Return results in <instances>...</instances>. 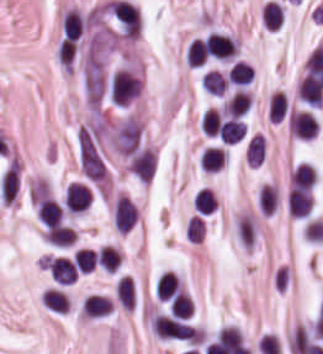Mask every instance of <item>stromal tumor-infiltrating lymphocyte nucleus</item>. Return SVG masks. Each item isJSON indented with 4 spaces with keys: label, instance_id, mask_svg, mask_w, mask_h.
Instances as JSON below:
<instances>
[{
    "label": "stromal tumor-infiltrating lymphocyte nucleus",
    "instance_id": "bc302bb0",
    "mask_svg": "<svg viewBox=\"0 0 323 354\" xmlns=\"http://www.w3.org/2000/svg\"><path fill=\"white\" fill-rule=\"evenodd\" d=\"M109 9L125 38L136 39L141 28L137 8L126 1H113Z\"/></svg>",
    "mask_w": 323,
    "mask_h": 354
},
{
    "label": "stromal tumor-infiltrating lymphocyte nucleus",
    "instance_id": "52c7bb5b",
    "mask_svg": "<svg viewBox=\"0 0 323 354\" xmlns=\"http://www.w3.org/2000/svg\"><path fill=\"white\" fill-rule=\"evenodd\" d=\"M288 130L296 136L311 139L316 135L317 120L305 110H292L289 116Z\"/></svg>",
    "mask_w": 323,
    "mask_h": 354
},
{
    "label": "stromal tumor-infiltrating lymphocyte nucleus",
    "instance_id": "3290ff9b",
    "mask_svg": "<svg viewBox=\"0 0 323 354\" xmlns=\"http://www.w3.org/2000/svg\"><path fill=\"white\" fill-rule=\"evenodd\" d=\"M210 56L232 58L237 53V43L229 35L211 33L204 40Z\"/></svg>",
    "mask_w": 323,
    "mask_h": 354
},
{
    "label": "stromal tumor-infiltrating lymphocyte nucleus",
    "instance_id": "abfb95fc",
    "mask_svg": "<svg viewBox=\"0 0 323 354\" xmlns=\"http://www.w3.org/2000/svg\"><path fill=\"white\" fill-rule=\"evenodd\" d=\"M313 207L309 191L292 188L287 197V209L291 218H304Z\"/></svg>",
    "mask_w": 323,
    "mask_h": 354
},
{
    "label": "stromal tumor-infiltrating lymphocyte nucleus",
    "instance_id": "9ea309e8",
    "mask_svg": "<svg viewBox=\"0 0 323 354\" xmlns=\"http://www.w3.org/2000/svg\"><path fill=\"white\" fill-rule=\"evenodd\" d=\"M47 267L51 278L60 284H68L77 278V267L63 256L52 257Z\"/></svg>",
    "mask_w": 323,
    "mask_h": 354
},
{
    "label": "stromal tumor-infiltrating lymphocyte nucleus",
    "instance_id": "f3e2335f",
    "mask_svg": "<svg viewBox=\"0 0 323 354\" xmlns=\"http://www.w3.org/2000/svg\"><path fill=\"white\" fill-rule=\"evenodd\" d=\"M136 220V209L131 200L119 195L115 205L113 222L119 231H128Z\"/></svg>",
    "mask_w": 323,
    "mask_h": 354
},
{
    "label": "stromal tumor-infiltrating lymphocyte nucleus",
    "instance_id": "4f13568d",
    "mask_svg": "<svg viewBox=\"0 0 323 354\" xmlns=\"http://www.w3.org/2000/svg\"><path fill=\"white\" fill-rule=\"evenodd\" d=\"M297 93L300 99L312 107H320L323 100V86L314 75L307 73L302 78Z\"/></svg>",
    "mask_w": 323,
    "mask_h": 354
},
{
    "label": "stromal tumor-infiltrating lymphocyte nucleus",
    "instance_id": "2a367800",
    "mask_svg": "<svg viewBox=\"0 0 323 354\" xmlns=\"http://www.w3.org/2000/svg\"><path fill=\"white\" fill-rule=\"evenodd\" d=\"M91 199L90 189L79 182H72L65 195L66 205L76 213L88 208Z\"/></svg>",
    "mask_w": 323,
    "mask_h": 354
},
{
    "label": "stromal tumor-infiltrating lymphocyte nucleus",
    "instance_id": "4803ca6d",
    "mask_svg": "<svg viewBox=\"0 0 323 354\" xmlns=\"http://www.w3.org/2000/svg\"><path fill=\"white\" fill-rule=\"evenodd\" d=\"M19 189V168L18 162L13 157L9 163L2 179L1 193L3 203H10L14 200Z\"/></svg>",
    "mask_w": 323,
    "mask_h": 354
},
{
    "label": "stromal tumor-infiltrating lymphocyte nucleus",
    "instance_id": "4245b91a",
    "mask_svg": "<svg viewBox=\"0 0 323 354\" xmlns=\"http://www.w3.org/2000/svg\"><path fill=\"white\" fill-rule=\"evenodd\" d=\"M266 153L263 134L250 133L244 142V157L249 163L260 164Z\"/></svg>",
    "mask_w": 323,
    "mask_h": 354
},
{
    "label": "stromal tumor-infiltrating lymphocyte nucleus",
    "instance_id": "4c9ddf68",
    "mask_svg": "<svg viewBox=\"0 0 323 354\" xmlns=\"http://www.w3.org/2000/svg\"><path fill=\"white\" fill-rule=\"evenodd\" d=\"M113 303L102 294H88L83 305L82 315L100 317L108 315Z\"/></svg>",
    "mask_w": 323,
    "mask_h": 354
},
{
    "label": "stromal tumor-infiltrating lymphocyte nucleus",
    "instance_id": "2761f720",
    "mask_svg": "<svg viewBox=\"0 0 323 354\" xmlns=\"http://www.w3.org/2000/svg\"><path fill=\"white\" fill-rule=\"evenodd\" d=\"M45 238L56 247H69L77 238L73 229L67 225H54L47 228Z\"/></svg>",
    "mask_w": 323,
    "mask_h": 354
},
{
    "label": "stromal tumor-infiltrating lymphocyte nucleus",
    "instance_id": "3c572f05",
    "mask_svg": "<svg viewBox=\"0 0 323 354\" xmlns=\"http://www.w3.org/2000/svg\"><path fill=\"white\" fill-rule=\"evenodd\" d=\"M83 17L76 9H68L63 14L62 30L67 40H77L83 31Z\"/></svg>",
    "mask_w": 323,
    "mask_h": 354
},
{
    "label": "stromal tumor-infiltrating lymphocyte nucleus",
    "instance_id": "42bb06b2",
    "mask_svg": "<svg viewBox=\"0 0 323 354\" xmlns=\"http://www.w3.org/2000/svg\"><path fill=\"white\" fill-rule=\"evenodd\" d=\"M253 78L252 67L248 62L235 61L231 67L226 81L237 86L250 84Z\"/></svg>",
    "mask_w": 323,
    "mask_h": 354
},
{
    "label": "stromal tumor-infiltrating lymphocyte nucleus",
    "instance_id": "9e4306bb",
    "mask_svg": "<svg viewBox=\"0 0 323 354\" xmlns=\"http://www.w3.org/2000/svg\"><path fill=\"white\" fill-rule=\"evenodd\" d=\"M245 134L241 119L231 117L221 123L220 135L225 144H236Z\"/></svg>",
    "mask_w": 323,
    "mask_h": 354
},
{
    "label": "stromal tumor-infiltrating lymphocyte nucleus",
    "instance_id": "04cf8593",
    "mask_svg": "<svg viewBox=\"0 0 323 354\" xmlns=\"http://www.w3.org/2000/svg\"><path fill=\"white\" fill-rule=\"evenodd\" d=\"M316 180L315 172L308 162H300L293 170L291 181L293 187L311 188Z\"/></svg>",
    "mask_w": 323,
    "mask_h": 354
},
{
    "label": "stromal tumor-infiltrating lymphocyte nucleus",
    "instance_id": "e9af9c67",
    "mask_svg": "<svg viewBox=\"0 0 323 354\" xmlns=\"http://www.w3.org/2000/svg\"><path fill=\"white\" fill-rule=\"evenodd\" d=\"M38 212L45 226H52L61 220L58 204L52 199L40 198Z\"/></svg>",
    "mask_w": 323,
    "mask_h": 354
},
{
    "label": "stromal tumor-infiltrating lymphocyte nucleus",
    "instance_id": "782c7336",
    "mask_svg": "<svg viewBox=\"0 0 323 354\" xmlns=\"http://www.w3.org/2000/svg\"><path fill=\"white\" fill-rule=\"evenodd\" d=\"M96 261L105 272H114L119 267L118 251L113 247L101 246L98 249Z\"/></svg>",
    "mask_w": 323,
    "mask_h": 354
},
{
    "label": "stromal tumor-infiltrating lymphocyte nucleus",
    "instance_id": "cac63f63",
    "mask_svg": "<svg viewBox=\"0 0 323 354\" xmlns=\"http://www.w3.org/2000/svg\"><path fill=\"white\" fill-rule=\"evenodd\" d=\"M278 204V191L271 185H263L258 196L259 209L263 215H272Z\"/></svg>",
    "mask_w": 323,
    "mask_h": 354
},
{
    "label": "stromal tumor-infiltrating lymphocyte nucleus",
    "instance_id": "2e467ee5",
    "mask_svg": "<svg viewBox=\"0 0 323 354\" xmlns=\"http://www.w3.org/2000/svg\"><path fill=\"white\" fill-rule=\"evenodd\" d=\"M43 304L57 313H66L68 309V299L64 292L57 288H49L44 291Z\"/></svg>",
    "mask_w": 323,
    "mask_h": 354
},
{
    "label": "stromal tumor-infiltrating lymphocyte nucleus",
    "instance_id": "7eef579d",
    "mask_svg": "<svg viewBox=\"0 0 323 354\" xmlns=\"http://www.w3.org/2000/svg\"><path fill=\"white\" fill-rule=\"evenodd\" d=\"M208 57L205 41L193 39L187 48L188 67H199Z\"/></svg>",
    "mask_w": 323,
    "mask_h": 354
},
{
    "label": "stromal tumor-infiltrating lymphocyte nucleus",
    "instance_id": "c26a33f6",
    "mask_svg": "<svg viewBox=\"0 0 323 354\" xmlns=\"http://www.w3.org/2000/svg\"><path fill=\"white\" fill-rule=\"evenodd\" d=\"M224 165V151L216 146H209L202 154L204 171L217 172Z\"/></svg>",
    "mask_w": 323,
    "mask_h": 354
},
{
    "label": "stromal tumor-infiltrating lymphocyte nucleus",
    "instance_id": "3e0999b9",
    "mask_svg": "<svg viewBox=\"0 0 323 354\" xmlns=\"http://www.w3.org/2000/svg\"><path fill=\"white\" fill-rule=\"evenodd\" d=\"M194 210L198 214H208L215 208V196L209 187H202L193 198Z\"/></svg>",
    "mask_w": 323,
    "mask_h": 354
},
{
    "label": "stromal tumor-infiltrating lymphocyte nucleus",
    "instance_id": "a0a3295f",
    "mask_svg": "<svg viewBox=\"0 0 323 354\" xmlns=\"http://www.w3.org/2000/svg\"><path fill=\"white\" fill-rule=\"evenodd\" d=\"M200 86L204 91L221 95L226 88V78L216 71H209L204 74Z\"/></svg>",
    "mask_w": 323,
    "mask_h": 354
},
{
    "label": "stromal tumor-infiltrating lymphocyte nucleus",
    "instance_id": "b6af03f8",
    "mask_svg": "<svg viewBox=\"0 0 323 354\" xmlns=\"http://www.w3.org/2000/svg\"><path fill=\"white\" fill-rule=\"evenodd\" d=\"M200 125L207 135H219L221 131V117L213 107L204 112Z\"/></svg>",
    "mask_w": 323,
    "mask_h": 354
},
{
    "label": "stromal tumor-infiltrating lymphocyte nucleus",
    "instance_id": "6c763739",
    "mask_svg": "<svg viewBox=\"0 0 323 354\" xmlns=\"http://www.w3.org/2000/svg\"><path fill=\"white\" fill-rule=\"evenodd\" d=\"M97 252L79 248L72 255L77 269L83 272H91L94 269Z\"/></svg>",
    "mask_w": 323,
    "mask_h": 354
},
{
    "label": "stromal tumor-infiltrating lymphocyte nucleus",
    "instance_id": "fa64b396",
    "mask_svg": "<svg viewBox=\"0 0 323 354\" xmlns=\"http://www.w3.org/2000/svg\"><path fill=\"white\" fill-rule=\"evenodd\" d=\"M284 116V94L273 92L270 96L268 120L279 123Z\"/></svg>",
    "mask_w": 323,
    "mask_h": 354
},
{
    "label": "stromal tumor-infiltrating lymphocyte nucleus",
    "instance_id": "21d57d70",
    "mask_svg": "<svg viewBox=\"0 0 323 354\" xmlns=\"http://www.w3.org/2000/svg\"><path fill=\"white\" fill-rule=\"evenodd\" d=\"M194 313V303L189 294H184L175 301L172 315L179 319H187Z\"/></svg>",
    "mask_w": 323,
    "mask_h": 354
},
{
    "label": "stromal tumor-infiltrating lymphocyte nucleus",
    "instance_id": "02f42fee",
    "mask_svg": "<svg viewBox=\"0 0 323 354\" xmlns=\"http://www.w3.org/2000/svg\"><path fill=\"white\" fill-rule=\"evenodd\" d=\"M184 290L179 278L162 299L165 304H183Z\"/></svg>",
    "mask_w": 323,
    "mask_h": 354
}]
</instances>
